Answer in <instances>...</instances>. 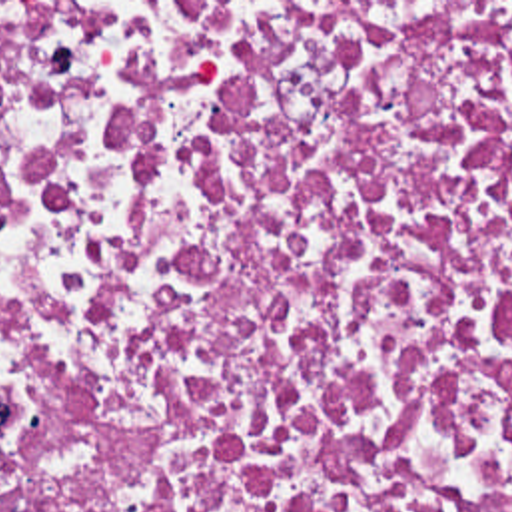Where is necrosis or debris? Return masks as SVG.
<instances>
[{
	"label": "necrosis or debris",
	"mask_w": 512,
	"mask_h": 512,
	"mask_svg": "<svg viewBox=\"0 0 512 512\" xmlns=\"http://www.w3.org/2000/svg\"><path fill=\"white\" fill-rule=\"evenodd\" d=\"M0 512H512V2H0Z\"/></svg>",
	"instance_id": "1"
}]
</instances>
